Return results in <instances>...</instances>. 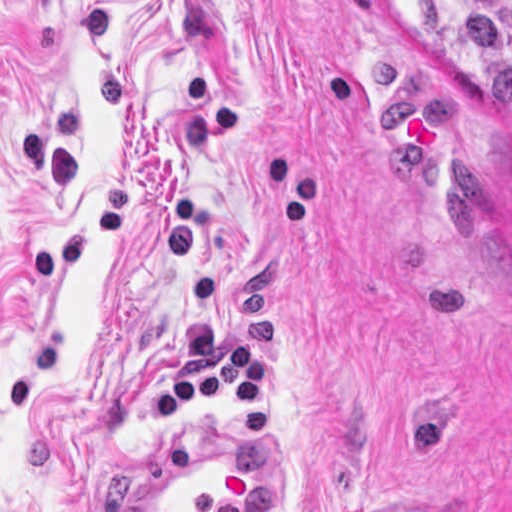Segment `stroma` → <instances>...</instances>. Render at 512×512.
<instances>
[{
    "label": "stroma",
    "instance_id": "1",
    "mask_svg": "<svg viewBox=\"0 0 512 512\" xmlns=\"http://www.w3.org/2000/svg\"><path fill=\"white\" fill-rule=\"evenodd\" d=\"M212 419L281 512H512V111L444 2L0 0V512Z\"/></svg>",
    "mask_w": 512,
    "mask_h": 512
}]
</instances>
